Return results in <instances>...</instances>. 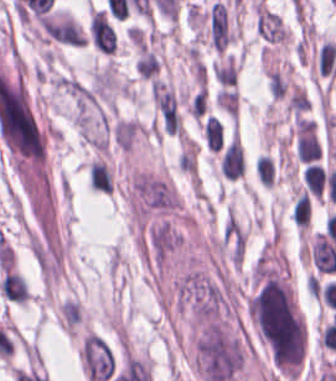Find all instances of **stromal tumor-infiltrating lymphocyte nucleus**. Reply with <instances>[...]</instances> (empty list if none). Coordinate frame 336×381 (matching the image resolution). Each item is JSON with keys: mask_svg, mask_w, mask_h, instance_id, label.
I'll list each match as a JSON object with an SVG mask.
<instances>
[{"mask_svg": "<svg viewBox=\"0 0 336 381\" xmlns=\"http://www.w3.org/2000/svg\"><path fill=\"white\" fill-rule=\"evenodd\" d=\"M254 174L261 187L271 189L274 183V164L269 155L259 154L254 164Z\"/></svg>", "mask_w": 336, "mask_h": 381, "instance_id": "9ea309e8", "label": "stromal tumor-infiltrating lymphocyte nucleus"}, {"mask_svg": "<svg viewBox=\"0 0 336 381\" xmlns=\"http://www.w3.org/2000/svg\"><path fill=\"white\" fill-rule=\"evenodd\" d=\"M88 35L91 45L97 51L112 55L115 33L105 12L101 9L90 8Z\"/></svg>", "mask_w": 336, "mask_h": 381, "instance_id": "52c7bb5b", "label": "stromal tumor-infiltrating lymphocyte nucleus"}, {"mask_svg": "<svg viewBox=\"0 0 336 381\" xmlns=\"http://www.w3.org/2000/svg\"><path fill=\"white\" fill-rule=\"evenodd\" d=\"M87 179L90 189L93 191L110 194V175L107 167L99 160L92 159L87 166Z\"/></svg>", "mask_w": 336, "mask_h": 381, "instance_id": "abfb95fc", "label": "stromal tumor-infiltrating lymphocyte nucleus"}, {"mask_svg": "<svg viewBox=\"0 0 336 381\" xmlns=\"http://www.w3.org/2000/svg\"><path fill=\"white\" fill-rule=\"evenodd\" d=\"M254 30L264 42L285 45L286 29L281 19L259 0L254 7Z\"/></svg>", "mask_w": 336, "mask_h": 381, "instance_id": "bc302bb0", "label": "stromal tumor-infiltrating lymphocyte nucleus"}, {"mask_svg": "<svg viewBox=\"0 0 336 381\" xmlns=\"http://www.w3.org/2000/svg\"><path fill=\"white\" fill-rule=\"evenodd\" d=\"M244 167V152L238 139L233 137L222 152L218 169L227 180H235L243 175Z\"/></svg>", "mask_w": 336, "mask_h": 381, "instance_id": "3290ff9b", "label": "stromal tumor-infiltrating lymphocyte nucleus"}]
</instances>
